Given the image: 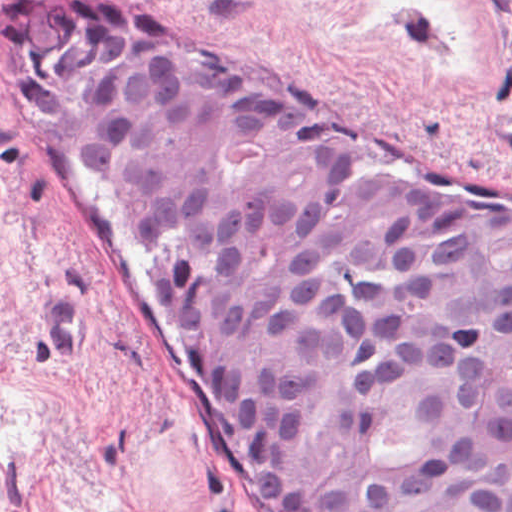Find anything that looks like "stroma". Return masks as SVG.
Listing matches in <instances>:
<instances>
[{"label":"stroma","instance_id":"1","mask_svg":"<svg viewBox=\"0 0 512 512\" xmlns=\"http://www.w3.org/2000/svg\"><path fill=\"white\" fill-rule=\"evenodd\" d=\"M0 0V512H274L259 452L74 132L15 61ZM365 131L512 192V0H110Z\"/></svg>","mask_w":512,"mask_h":512}]
</instances>
